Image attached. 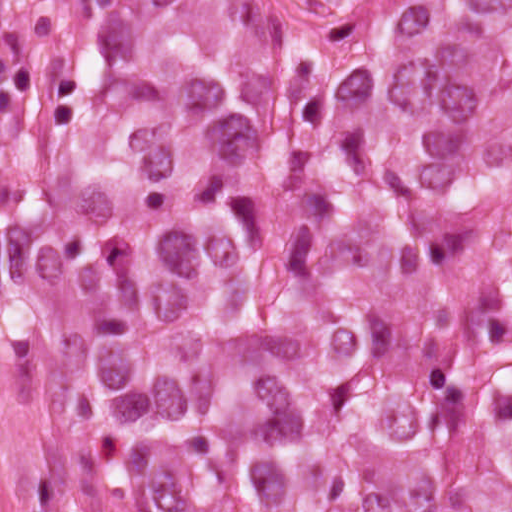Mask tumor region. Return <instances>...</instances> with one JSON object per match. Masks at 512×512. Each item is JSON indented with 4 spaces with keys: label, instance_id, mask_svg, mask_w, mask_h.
<instances>
[{
    "label": "tumor region",
    "instance_id": "e687c5a6",
    "mask_svg": "<svg viewBox=\"0 0 512 512\" xmlns=\"http://www.w3.org/2000/svg\"><path fill=\"white\" fill-rule=\"evenodd\" d=\"M71 0L59 411L94 512H512V0Z\"/></svg>",
    "mask_w": 512,
    "mask_h": 512
}]
</instances>
